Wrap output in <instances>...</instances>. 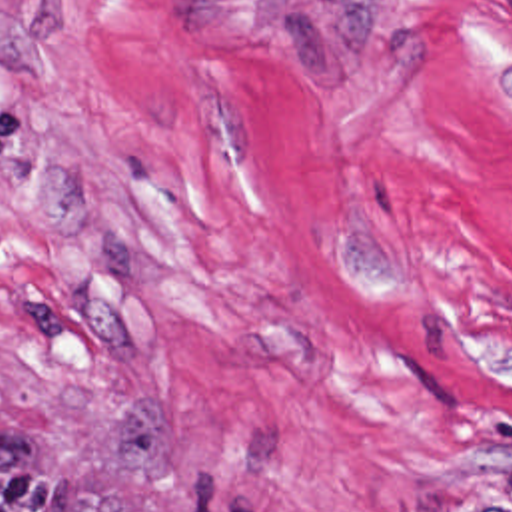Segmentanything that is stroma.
Here are the masks:
<instances>
[{"label": "stroma", "mask_w": 512, "mask_h": 512, "mask_svg": "<svg viewBox=\"0 0 512 512\" xmlns=\"http://www.w3.org/2000/svg\"><path fill=\"white\" fill-rule=\"evenodd\" d=\"M0 438L129 512H405L512 461V0H0Z\"/></svg>", "instance_id": "stroma-1"}]
</instances>
